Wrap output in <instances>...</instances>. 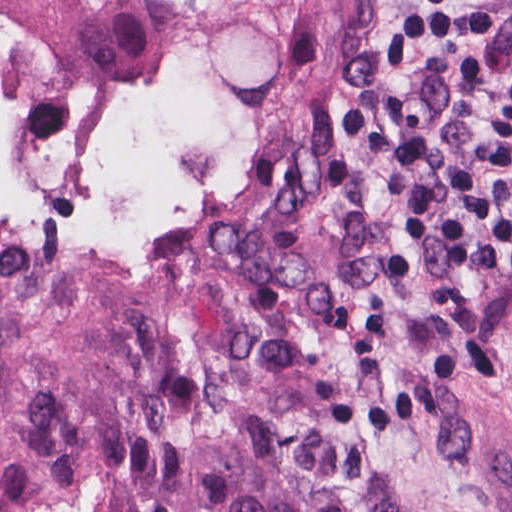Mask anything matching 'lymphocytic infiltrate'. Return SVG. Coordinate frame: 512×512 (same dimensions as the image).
Returning <instances> with one entry per match:
<instances>
[{
  "label": "lymphocytic infiltrate",
  "instance_id": "f902f5d3",
  "mask_svg": "<svg viewBox=\"0 0 512 512\" xmlns=\"http://www.w3.org/2000/svg\"><path fill=\"white\" fill-rule=\"evenodd\" d=\"M495 0H398L337 99L366 142L369 199L447 260L484 256L512 282V88L487 73Z\"/></svg>",
  "mask_w": 512,
  "mask_h": 512
}]
</instances>
